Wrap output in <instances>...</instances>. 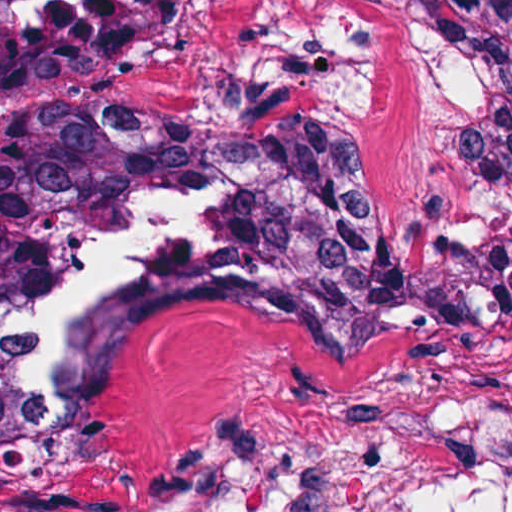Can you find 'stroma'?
Listing matches in <instances>:
<instances>
[{"mask_svg":"<svg viewBox=\"0 0 512 512\" xmlns=\"http://www.w3.org/2000/svg\"><path fill=\"white\" fill-rule=\"evenodd\" d=\"M115 104L218 135L306 129L366 175L391 266L187 301L115 355L101 449L53 485L0 372V512H512V373L463 288L421 269L489 245L467 89L411 0H183Z\"/></svg>","mask_w":512,"mask_h":512,"instance_id":"35a3bbf8","label":"stroma"}]
</instances>
